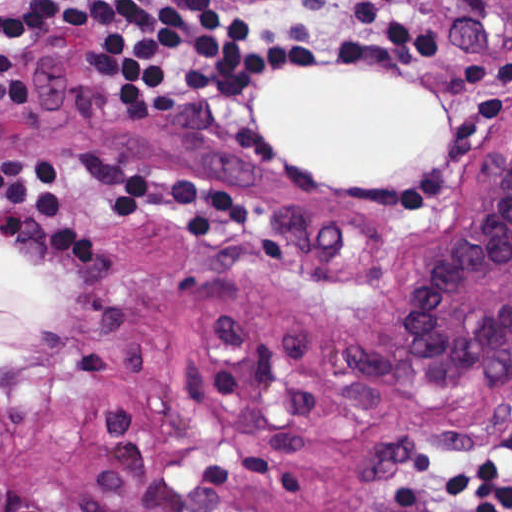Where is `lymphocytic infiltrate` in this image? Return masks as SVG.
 Here are the masks:
<instances>
[{"instance_id": "1", "label": "lymphocytic infiltrate", "mask_w": 512, "mask_h": 512, "mask_svg": "<svg viewBox=\"0 0 512 512\" xmlns=\"http://www.w3.org/2000/svg\"><path fill=\"white\" fill-rule=\"evenodd\" d=\"M46 38L100 55L117 109L164 113L256 81L430 66L451 27L433 0H21L1 12L2 62ZM386 512H512V419Z\"/></svg>"}]
</instances>
